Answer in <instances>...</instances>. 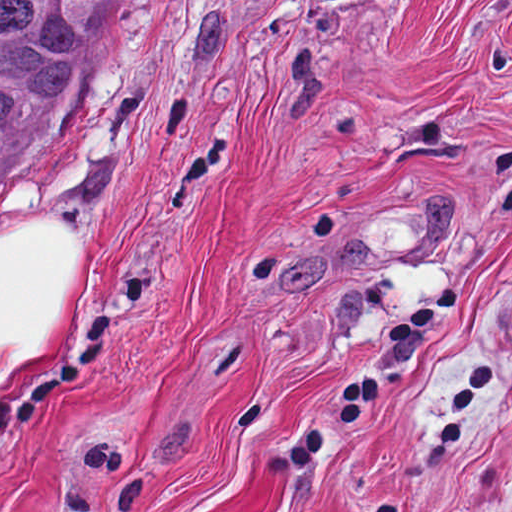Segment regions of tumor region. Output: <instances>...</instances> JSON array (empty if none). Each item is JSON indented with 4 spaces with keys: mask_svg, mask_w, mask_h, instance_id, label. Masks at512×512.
<instances>
[{
    "mask_svg": "<svg viewBox=\"0 0 512 512\" xmlns=\"http://www.w3.org/2000/svg\"><path fill=\"white\" fill-rule=\"evenodd\" d=\"M111 0H0V160L53 117Z\"/></svg>",
    "mask_w": 512,
    "mask_h": 512,
    "instance_id": "e687c5a6",
    "label": "tumor region"
}]
</instances>
